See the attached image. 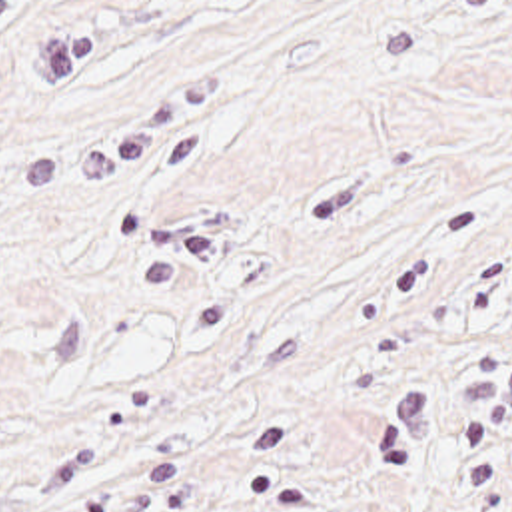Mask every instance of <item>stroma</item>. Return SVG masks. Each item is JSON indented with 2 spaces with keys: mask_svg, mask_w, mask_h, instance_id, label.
<instances>
[{
  "mask_svg": "<svg viewBox=\"0 0 512 512\" xmlns=\"http://www.w3.org/2000/svg\"><path fill=\"white\" fill-rule=\"evenodd\" d=\"M0 512H512V0H0Z\"/></svg>",
  "mask_w": 512,
  "mask_h": 512,
  "instance_id": "1",
  "label": "stroma"
}]
</instances>
